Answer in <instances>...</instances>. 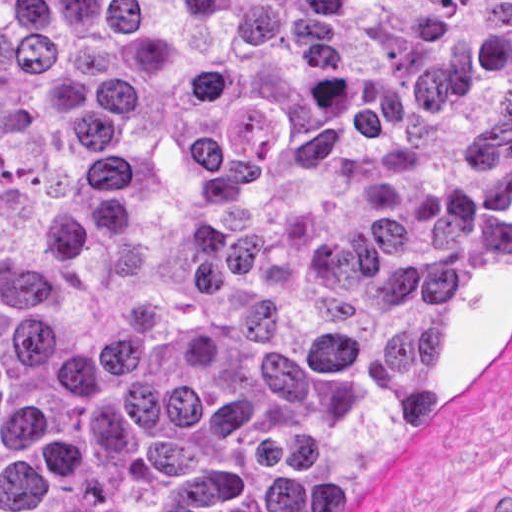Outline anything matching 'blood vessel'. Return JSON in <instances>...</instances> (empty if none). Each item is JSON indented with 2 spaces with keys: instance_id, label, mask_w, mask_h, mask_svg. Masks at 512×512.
Masks as SVG:
<instances>
[{
  "instance_id": "blood-vessel-1",
  "label": "blood vessel",
  "mask_w": 512,
  "mask_h": 512,
  "mask_svg": "<svg viewBox=\"0 0 512 512\" xmlns=\"http://www.w3.org/2000/svg\"><path fill=\"white\" fill-rule=\"evenodd\" d=\"M480 512H512V485L498 486Z\"/></svg>"
}]
</instances>
